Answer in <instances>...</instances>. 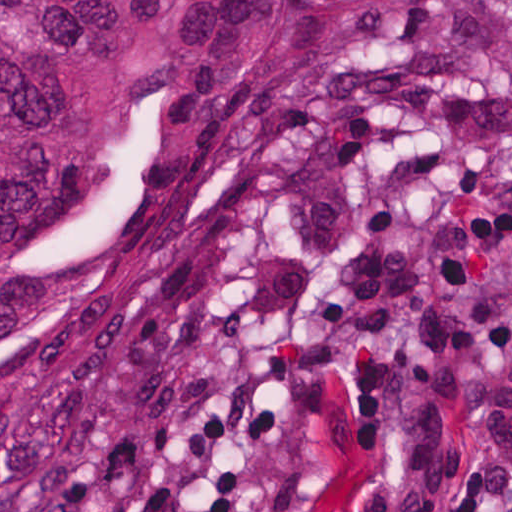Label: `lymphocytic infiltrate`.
I'll return each mask as SVG.
<instances>
[{"instance_id": "obj_1", "label": "lymphocytic infiltrate", "mask_w": 512, "mask_h": 512, "mask_svg": "<svg viewBox=\"0 0 512 512\" xmlns=\"http://www.w3.org/2000/svg\"><path fill=\"white\" fill-rule=\"evenodd\" d=\"M448 512H512V456H496L470 467Z\"/></svg>"}]
</instances>
